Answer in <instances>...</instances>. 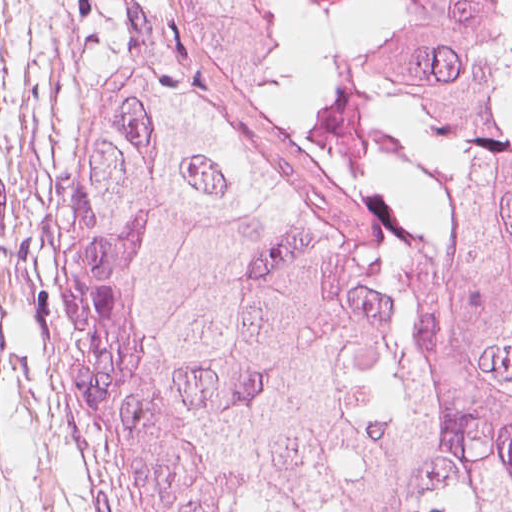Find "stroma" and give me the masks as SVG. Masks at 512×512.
<instances>
[{"mask_svg":"<svg viewBox=\"0 0 512 512\" xmlns=\"http://www.w3.org/2000/svg\"><path fill=\"white\" fill-rule=\"evenodd\" d=\"M109 0H0V512H96L55 393L62 178Z\"/></svg>","mask_w":512,"mask_h":512,"instance_id":"1","label":"stroma"}]
</instances>
